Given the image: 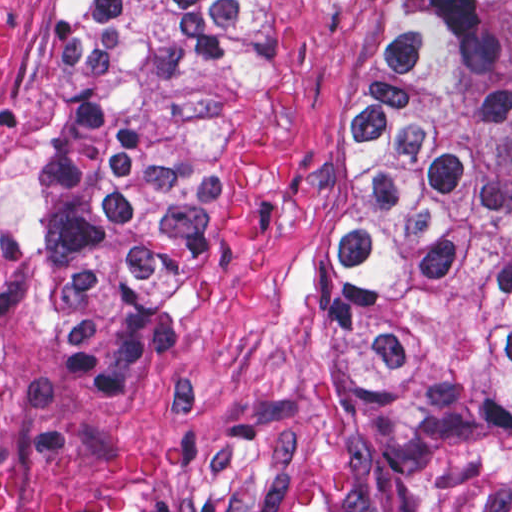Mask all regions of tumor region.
Here are the masks:
<instances>
[{
	"label": "tumor region",
	"instance_id": "e687c5a6",
	"mask_svg": "<svg viewBox=\"0 0 512 512\" xmlns=\"http://www.w3.org/2000/svg\"><path fill=\"white\" fill-rule=\"evenodd\" d=\"M78 57L6 213L84 357L139 363L228 275L223 96L261 0H62ZM332 380L381 457L512 494V0H393L327 234Z\"/></svg>",
	"mask_w": 512,
	"mask_h": 512
}]
</instances>
